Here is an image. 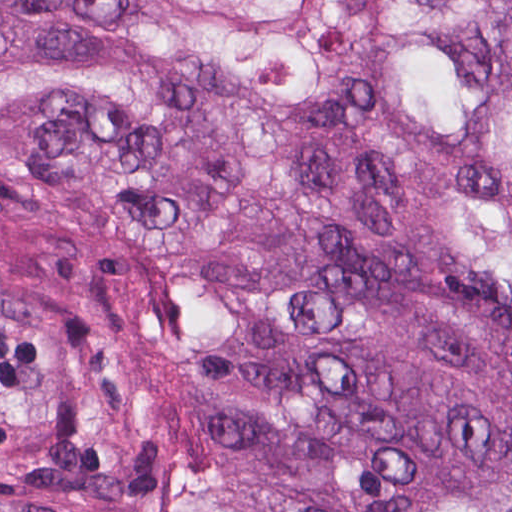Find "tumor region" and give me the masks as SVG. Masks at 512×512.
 Returning <instances> with one entry per match:
<instances>
[{"mask_svg": "<svg viewBox=\"0 0 512 512\" xmlns=\"http://www.w3.org/2000/svg\"><path fill=\"white\" fill-rule=\"evenodd\" d=\"M377 2L384 107L480 128L512 195V0ZM0 187L176 243L252 462L360 512H512V214L371 123L361 0H0ZM148 451L101 361L0 305V479ZM178 496L291 512L218 479Z\"/></svg>", "mask_w": 512, "mask_h": 512, "instance_id": "tumor-region-1", "label": "tumor region"}]
</instances>
